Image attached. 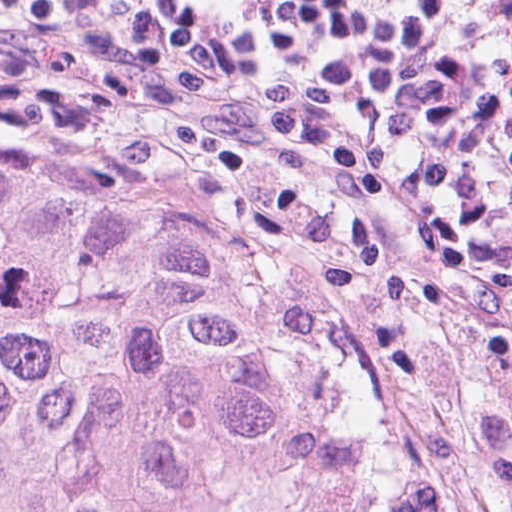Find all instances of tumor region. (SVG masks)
<instances>
[{
    "mask_svg": "<svg viewBox=\"0 0 512 512\" xmlns=\"http://www.w3.org/2000/svg\"><path fill=\"white\" fill-rule=\"evenodd\" d=\"M474 443L512 504V413ZM0 512H482L448 411L214 257L154 157L0 132Z\"/></svg>",
    "mask_w": 512,
    "mask_h": 512,
    "instance_id": "1",
    "label": "tumor region"
}]
</instances>
